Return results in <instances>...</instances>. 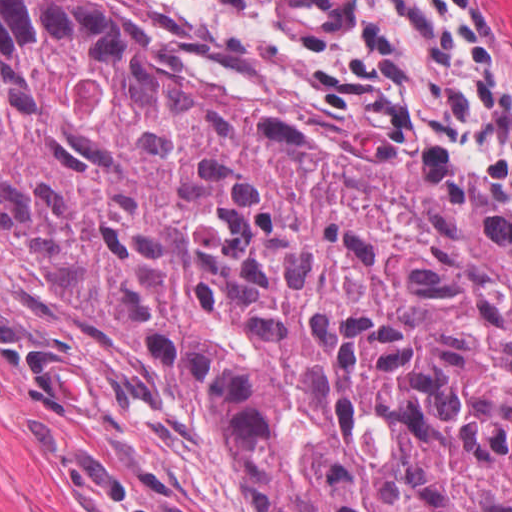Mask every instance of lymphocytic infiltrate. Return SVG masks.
I'll use <instances>...</instances> for the list:
<instances>
[{
    "label": "lymphocytic infiltrate",
    "mask_w": 512,
    "mask_h": 512,
    "mask_svg": "<svg viewBox=\"0 0 512 512\" xmlns=\"http://www.w3.org/2000/svg\"><path fill=\"white\" fill-rule=\"evenodd\" d=\"M379 116L421 124L512 185V53L479 0H228Z\"/></svg>",
    "instance_id": "f902f5d3"
}]
</instances>
